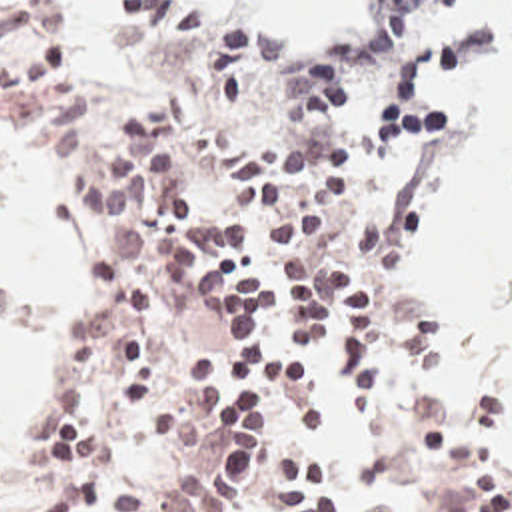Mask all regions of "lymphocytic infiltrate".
<instances>
[{
  "mask_svg": "<svg viewBox=\"0 0 512 512\" xmlns=\"http://www.w3.org/2000/svg\"><path fill=\"white\" fill-rule=\"evenodd\" d=\"M410 35L452 0H368ZM128 63L150 97H110L52 0H0V101L106 221V259L62 345V399L30 417L21 467L46 489L0 512H286L338 499L312 443L328 431L318 359L354 409H378L456 512H512L468 467L444 405L382 365L386 231L306 215L368 129L360 67L308 69L200 0H130Z\"/></svg>",
  "mask_w": 512,
  "mask_h": 512,
  "instance_id": "lymphocytic-infiltrate-1",
  "label": "lymphocytic infiltrate"
}]
</instances>
